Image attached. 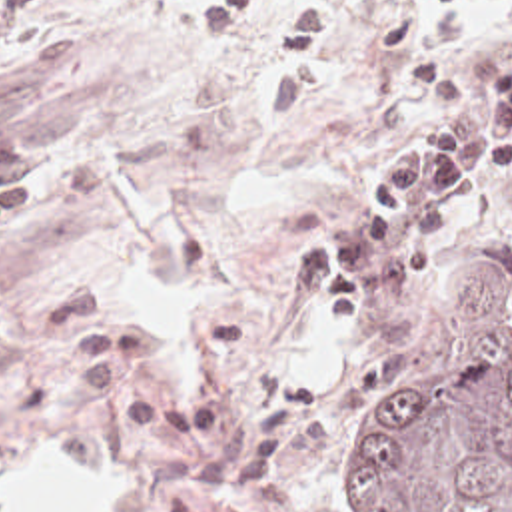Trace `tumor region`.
<instances>
[{"instance_id": "tumor-region-1", "label": "tumor region", "mask_w": 512, "mask_h": 512, "mask_svg": "<svg viewBox=\"0 0 512 512\" xmlns=\"http://www.w3.org/2000/svg\"><path fill=\"white\" fill-rule=\"evenodd\" d=\"M444 316L458 340L498 334L348 444L338 486L356 512H512V282L458 290Z\"/></svg>"}]
</instances>
